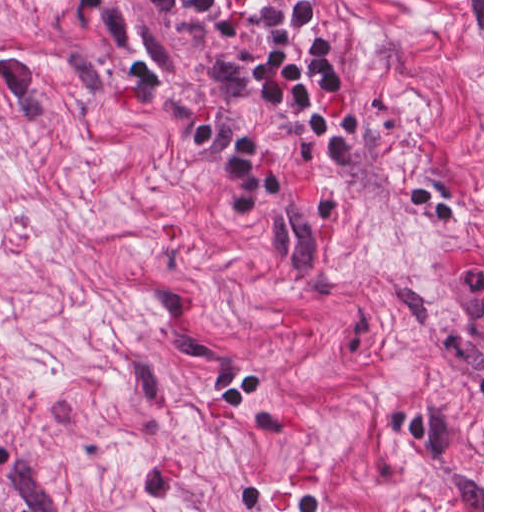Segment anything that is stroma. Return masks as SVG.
Here are the masks:
<instances>
[{
	"label": "stroma",
	"mask_w": 512,
	"mask_h": 512,
	"mask_svg": "<svg viewBox=\"0 0 512 512\" xmlns=\"http://www.w3.org/2000/svg\"><path fill=\"white\" fill-rule=\"evenodd\" d=\"M483 328L124 0H0V512H318Z\"/></svg>",
	"instance_id": "1"
}]
</instances>
